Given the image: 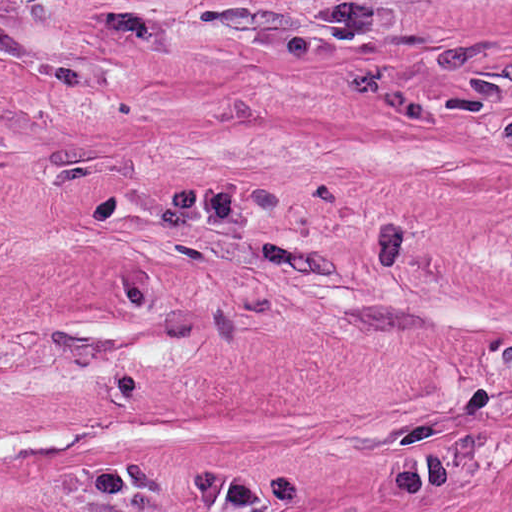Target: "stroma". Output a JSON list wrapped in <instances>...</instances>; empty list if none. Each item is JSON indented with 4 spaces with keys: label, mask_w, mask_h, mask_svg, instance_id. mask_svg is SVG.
<instances>
[{
    "label": "stroma",
    "mask_w": 512,
    "mask_h": 512,
    "mask_svg": "<svg viewBox=\"0 0 512 512\" xmlns=\"http://www.w3.org/2000/svg\"><path fill=\"white\" fill-rule=\"evenodd\" d=\"M0 131L512 297V0H0Z\"/></svg>",
    "instance_id": "obj_1"
}]
</instances>
